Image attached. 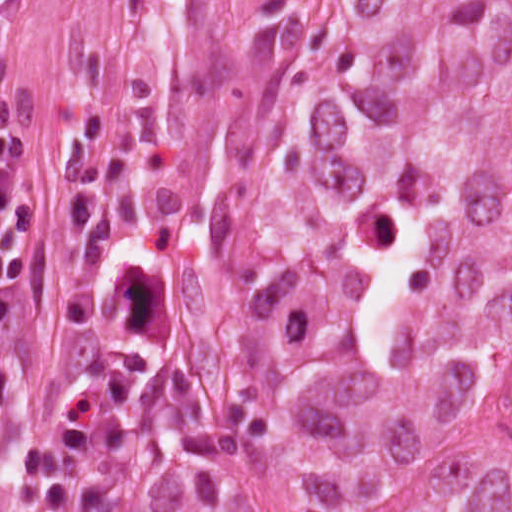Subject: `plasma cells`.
<instances>
[{
    "instance_id": "obj_1",
    "label": "plasma cells",
    "mask_w": 512,
    "mask_h": 512,
    "mask_svg": "<svg viewBox=\"0 0 512 512\" xmlns=\"http://www.w3.org/2000/svg\"><path fill=\"white\" fill-rule=\"evenodd\" d=\"M8 432V85H0V460Z\"/></svg>"
}]
</instances>
